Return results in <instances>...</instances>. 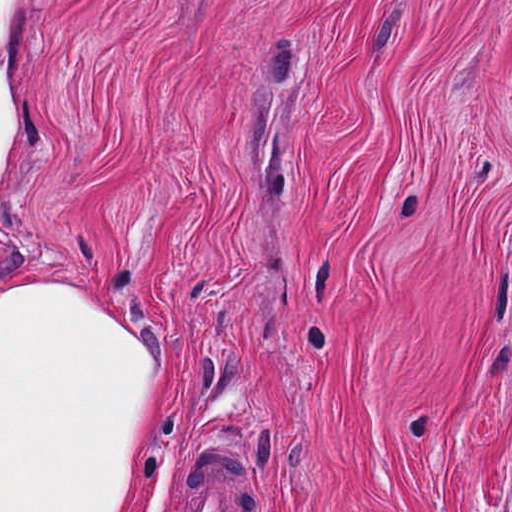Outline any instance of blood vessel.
<instances>
[{
	"label": "blood vessel",
	"instance_id": "8fb6f2fc",
	"mask_svg": "<svg viewBox=\"0 0 512 512\" xmlns=\"http://www.w3.org/2000/svg\"><path fill=\"white\" fill-rule=\"evenodd\" d=\"M218 443L222 448L210 449L192 476L179 512H251L250 486L229 448Z\"/></svg>",
	"mask_w": 512,
	"mask_h": 512
}]
</instances>
